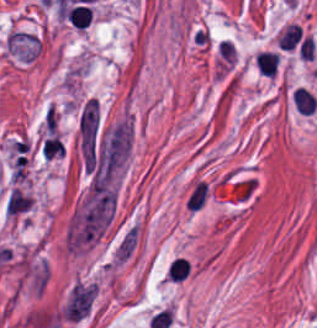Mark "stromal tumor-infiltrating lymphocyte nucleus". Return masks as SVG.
<instances>
[{
	"instance_id": "bc302bb0",
	"label": "stromal tumor-infiltrating lymphocyte nucleus",
	"mask_w": 317,
	"mask_h": 328,
	"mask_svg": "<svg viewBox=\"0 0 317 328\" xmlns=\"http://www.w3.org/2000/svg\"><path fill=\"white\" fill-rule=\"evenodd\" d=\"M300 37V26L296 22H289L279 31L276 47L292 49Z\"/></svg>"
},
{
	"instance_id": "52c7bb5b",
	"label": "stromal tumor-infiltrating lymphocyte nucleus",
	"mask_w": 317,
	"mask_h": 328,
	"mask_svg": "<svg viewBox=\"0 0 317 328\" xmlns=\"http://www.w3.org/2000/svg\"><path fill=\"white\" fill-rule=\"evenodd\" d=\"M65 18L73 26L82 30L91 20V8L80 4L70 5Z\"/></svg>"
},
{
	"instance_id": "3290ff9b",
	"label": "stromal tumor-infiltrating lymphocyte nucleus",
	"mask_w": 317,
	"mask_h": 328,
	"mask_svg": "<svg viewBox=\"0 0 317 328\" xmlns=\"http://www.w3.org/2000/svg\"><path fill=\"white\" fill-rule=\"evenodd\" d=\"M317 98L305 87L294 89V106L300 114H311Z\"/></svg>"
},
{
	"instance_id": "9ea309e8",
	"label": "stromal tumor-infiltrating lymphocyte nucleus",
	"mask_w": 317,
	"mask_h": 328,
	"mask_svg": "<svg viewBox=\"0 0 317 328\" xmlns=\"http://www.w3.org/2000/svg\"><path fill=\"white\" fill-rule=\"evenodd\" d=\"M190 269V263L181 257H174L168 266L167 276L170 280H181L185 278Z\"/></svg>"
},
{
	"instance_id": "abfb95fc",
	"label": "stromal tumor-infiltrating lymphocyte nucleus",
	"mask_w": 317,
	"mask_h": 328,
	"mask_svg": "<svg viewBox=\"0 0 317 328\" xmlns=\"http://www.w3.org/2000/svg\"><path fill=\"white\" fill-rule=\"evenodd\" d=\"M255 68L262 75H275L276 55L275 53L260 51L255 53Z\"/></svg>"
}]
</instances>
